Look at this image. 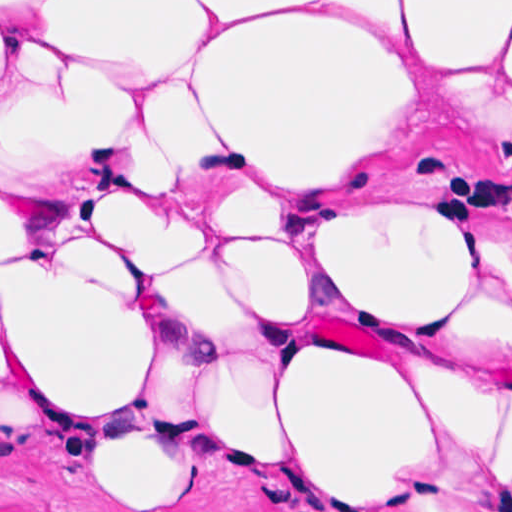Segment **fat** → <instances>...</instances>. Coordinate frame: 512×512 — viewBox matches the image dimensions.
<instances>
[{
  "mask_svg": "<svg viewBox=\"0 0 512 512\" xmlns=\"http://www.w3.org/2000/svg\"><path fill=\"white\" fill-rule=\"evenodd\" d=\"M512 1H0V385L103 473L512 506Z\"/></svg>",
  "mask_w": 512,
  "mask_h": 512,
  "instance_id": "53f6f03d",
  "label": "fat"
}]
</instances>
